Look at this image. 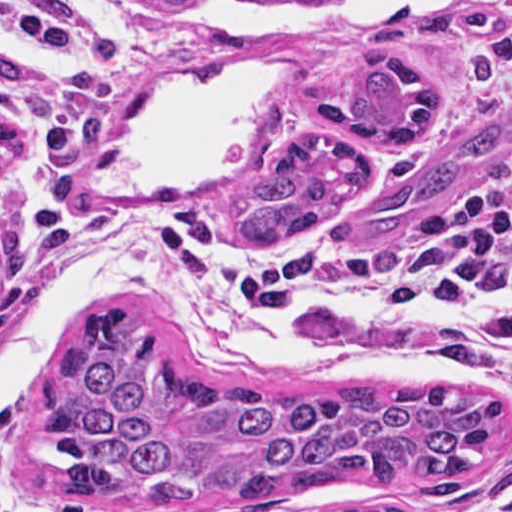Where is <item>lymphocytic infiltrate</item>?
I'll use <instances>...</instances> for the list:
<instances>
[{
  "instance_id": "obj_1",
  "label": "lymphocytic infiltrate",
  "mask_w": 512,
  "mask_h": 512,
  "mask_svg": "<svg viewBox=\"0 0 512 512\" xmlns=\"http://www.w3.org/2000/svg\"><path fill=\"white\" fill-rule=\"evenodd\" d=\"M0 28L49 51L64 68L41 79L0 56V103L29 122L34 151L53 166L81 161L113 108L114 40L85 19L2 3ZM228 228L210 208L161 209L152 270L164 283L283 316L309 301L351 296L382 316L426 317V306L441 298L512 291V193L439 216L427 243L411 252L334 254L304 240L254 250L233 244ZM435 322L439 353L459 375L477 380L504 355L512 359V312ZM0 512H29L14 487L9 420L1 410Z\"/></svg>"
}]
</instances>
